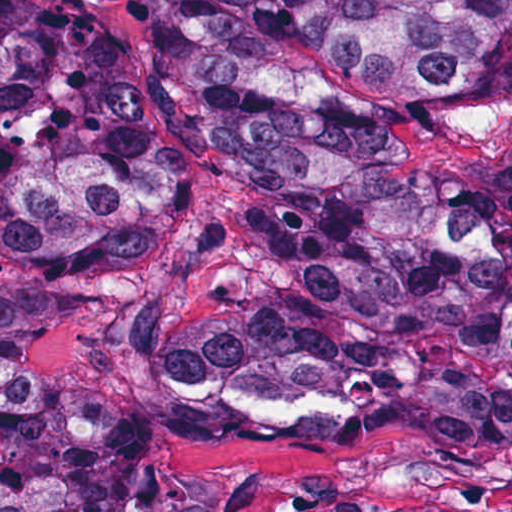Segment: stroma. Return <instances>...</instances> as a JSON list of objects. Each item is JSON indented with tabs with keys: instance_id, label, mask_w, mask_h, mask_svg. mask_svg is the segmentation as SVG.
<instances>
[{
	"instance_id": "stroma-1",
	"label": "stroma",
	"mask_w": 512,
	"mask_h": 512,
	"mask_svg": "<svg viewBox=\"0 0 512 512\" xmlns=\"http://www.w3.org/2000/svg\"><path fill=\"white\" fill-rule=\"evenodd\" d=\"M83 20H136L158 0H53ZM298 78L384 120L395 159L433 169L465 126L467 101H430L332 58L285 60ZM243 183L203 134L143 274L39 281L0 261V284L57 293L73 308L24 350L28 376L70 400L121 407L148 426L153 478L207 476L220 512H299L334 494L372 507L512 512V370L500 350H359L267 361L171 393L130 361L141 297L183 289L209 269L204 241L237 219ZM336 385L363 407L346 420H239L228 392Z\"/></svg>"
}]
</instances>
